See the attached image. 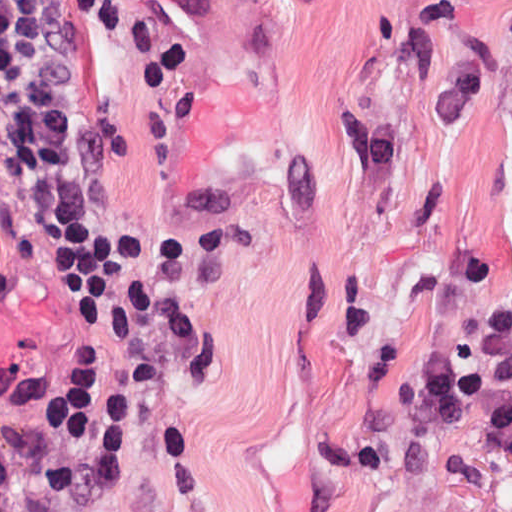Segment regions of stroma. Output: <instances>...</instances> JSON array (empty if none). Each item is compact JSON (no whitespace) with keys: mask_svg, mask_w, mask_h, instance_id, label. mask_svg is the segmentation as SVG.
Wrapping results in <instances>:
<instances>
[{"mask_svg":"<svg viewBox=\"0 0 512 512\" xmlns=\"http://www.w3.org/2000/svg\"><path fill=\"white\" fill-rule=\"evenodd\" d=\"M104 164L151 249L83 286L0 135V360L63 512H512L414 366L512 292V0H70ZM144 406L128 471L44 439L68 355Z\"/></svg>","mask_w":512,"mask_h":512,"instance_id":"stroma-1","label":"stroma"}]
</instances>
